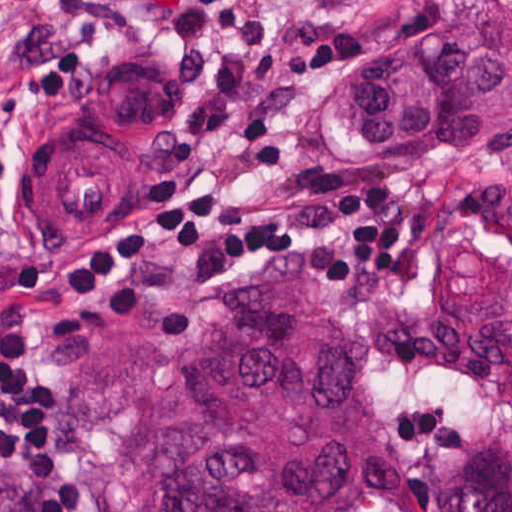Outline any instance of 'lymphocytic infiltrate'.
<instances>
[{
	"mask_svg": "<svg viewBox=\"0 0 512 512\" xmlns=\"http://www.w3.org/2000/svg\"><path fill=\"white\" fill-rule=\"evenodd\" d=\"M312 0H162L168 53L164 84L188 91L174 120L192 151L228 147L252 185L294 179L296 122L305 90L357 47L352 28L294 33ZM96 49L89 0H62L39 26L0 52V121L31 85L41 109L83 84ZM145 211L129 207L126 229L99 236L49 279L55 304L107 311L117 323L145 312L157 251L196 257L218 251L245 264L303 251L323 287L359 295L411 275L410 256L427 247V213L396 212L389 184H353L332 170L302 177L298 196L326 209L272 213L249 202L189 189L179 178L133 181ZM6 178L0 155V211ZM334 222V224H333ZM512 248V228L505 236ZM331 248V249H330ZM318 257L307 251H322ZM62 395L32 363V339L15 312L0 313V468L27 483L38 512H95L75 470L56 459L52 415ZM367 512H379L369 508Z\"/></svg>",
	"mask_w": 512,
	"mask_h": 512,
	"instance_id": "1",
	"label": "lymphocytic infiltrate"
}]
</instances>
